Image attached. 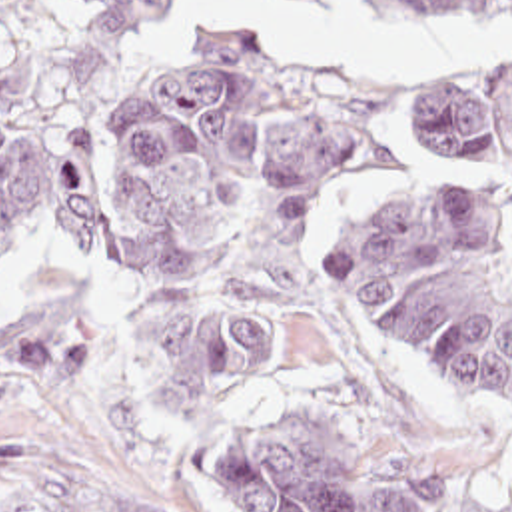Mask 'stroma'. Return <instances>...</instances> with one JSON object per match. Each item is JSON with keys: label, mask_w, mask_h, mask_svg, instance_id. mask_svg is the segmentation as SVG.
<instances>
[{"label": "stroma", "mask_w": 512, "mask_h": 512, "mask_svg": "<svg viewBox=\"0 0 512 512\" xmlns=\"http://www.w3.org/2000/svg\"><path fill=\"white\" fill-rule=\"evenodd\" d=\"M59 56L55 122L109 130L151 96L193 38H253L331 76L512 60V8L458 22L382 28L365 0L301 12L285 0H183L133 54H97L69 0H35ZM456 204L484 212L512 280V224L480 162L444 150L341 170L287 238L295 300L327 354L388 434L462 470L498 512H512V412L402 352L369 328L351 294L359 224L378 208ZM45 210L0 256V324L55 312L83 332V380L35 382L0 354V512H87L125 499L153 512H241L221 485L237 436L289 412L339 400L331 370L301 366L197 410H167V362L145 328L157 274L103 270L79 258ZM37 230V232H35Z\"/></svg>", "instance_id": "obj_1"}]
</instances>
